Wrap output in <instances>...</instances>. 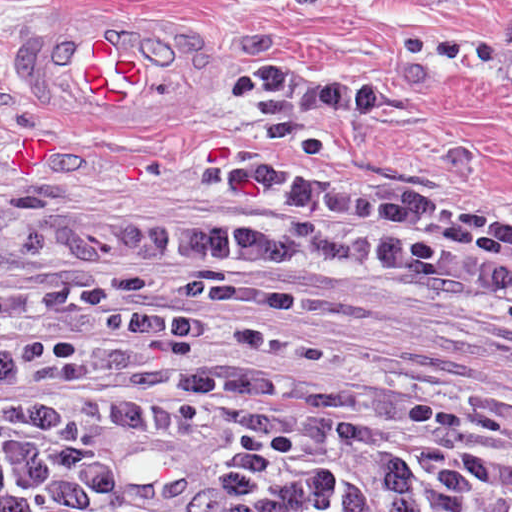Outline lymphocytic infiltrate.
<instances>
[{
    "instance_id": "f902f5d3",
    "label": "lymphocytic infiltrate",
    "mask_w": 512,
    "mask_h": 512,
    "mask_svg": "<svg viewBox=\"0 0 512 512\" xmlns=\"http://www.w3.org/2000/svg\"><path fill=\"white\" fill-rule=\"evenodd\" d=\"M223 88L237 97H281L324 113H394L390 85L322 83L281 65H252L227 78Z\"/></svg>"
}]
</instances>
